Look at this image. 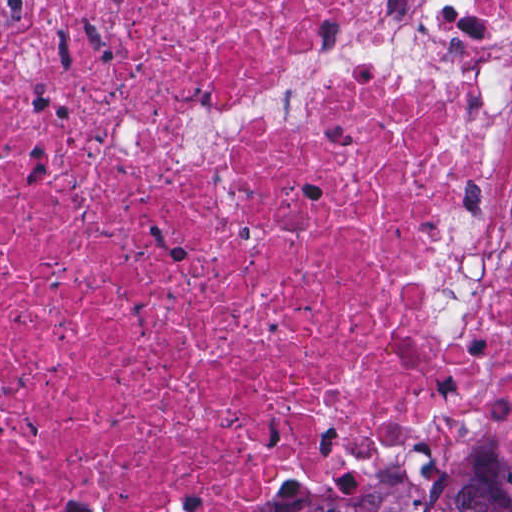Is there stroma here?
<instances>
[{
    "mask_svg": "<svg viewBox=\"0 0 512 512\" xmlns=\"http://www.w3.org/2000/svg\"><path fill=\"white\" fill-rule=\"evenodd\" d=\"M0 1H411L376 44L296 56L268 88L233 111H192L178 122L182 162L217 152L264 122L307 115L315 74L362 70L430 74L489 86L475 176L459 214L438 219L416 275L431 336L462 366L400 431L353 429L332 464H292L273 475L250 512H271L309 488L362 479L452 439L512 443V0H0Z\"/></svg>",
    "mask_w": 512,
    "mask_h": 512,
    "instance_id": "stroma-1",
    "label": "stroma"
}]
</instances>
